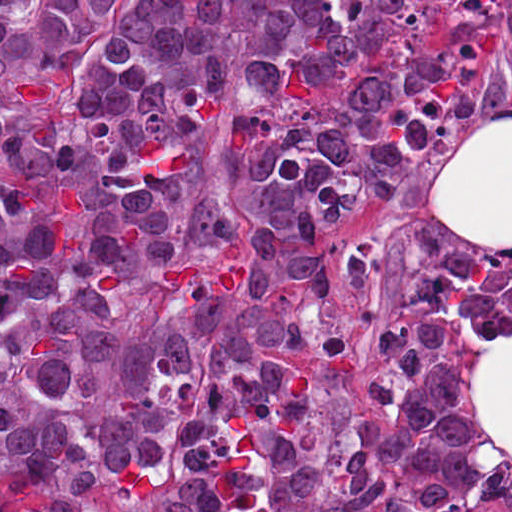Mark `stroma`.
Here are the masks:
<instances>
[{
    "label": "stroma",
    "instance_id": "obj_1",
    "mask_svg": "<svg viewBox=\"0 0 512 512\" xmlns=\"http://www.w3.org/2000/svg\"><path fill=\"white\" fill-rule=\"evenodd\" d=\"M485 112L512 114V33L504 22L494 41L483 105L453 119L425 164L408 171L384 213L339 233L331 247L334 298L323 300V321L302 353L332 418H366L379 350L404 286L419 269L453 256L512 260V250L468 248L433 205L446 157ZM480 512H512V476L488 482Z\"/></svg>",
    "mask_w": 512,
    "mask_h": 512
}]
</instances>
